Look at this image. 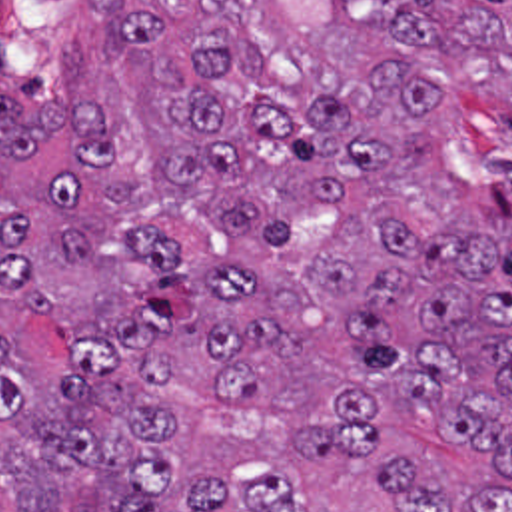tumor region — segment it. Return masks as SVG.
Masks as SVG:
<instances>
[{"label": "tumor region", "mask_w": 512, "mask_h": 512, "mask_svg": "<svg viewBox=\"0 0 512 512\" xmlns=\"http://www.w3.org/2000/svg\"><path fill=\"white\" fill-rule=\"evenodd\" d=\"M0 512H512V0L0 66Z\"/></svg>", "instance_id": "obj_1"}]
</instances>
